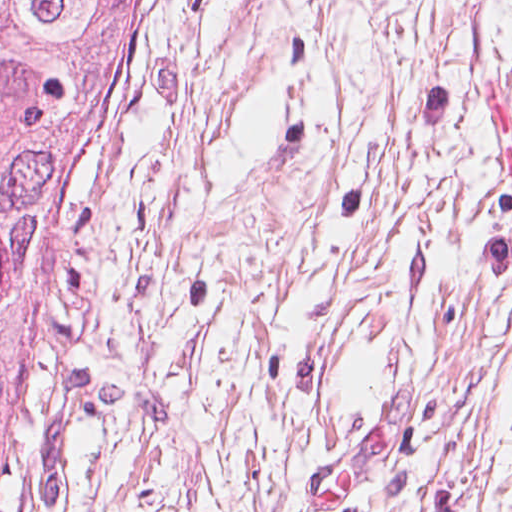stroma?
<instances>
[{
	"label": "stroma",
	"mask_w": 512,
	"mask_h": 512,
	"mask_svg": "<svg viewBox=\"0 0 512 512\" xmlns=\"http://www.w3.org/2000/svg\"><path fill=\"white\" fill-rule=\"evenodd\" d=\"M205 0H145L120 110L77 156L17 360L0 512H97Z\"/></svg>",
	"instance_id": "stroma-1"
}]
</instances>
